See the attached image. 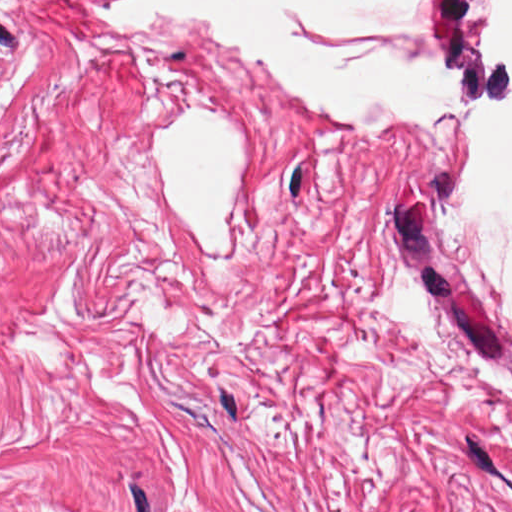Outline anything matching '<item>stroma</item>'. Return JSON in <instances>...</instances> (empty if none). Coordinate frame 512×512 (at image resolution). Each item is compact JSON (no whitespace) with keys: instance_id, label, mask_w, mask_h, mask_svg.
<instances>
[{"instance_id":"stroma-1","label":"stroma","mask_w":512,"mask_h":512,"mask_svg":"<svg viewBox=\"0 0 512 512\" xmlns=\"http://www.w3.org/2000/svg\"><path fill=\"white\" fill-rule=\"evenodd\" d=\"M450 188L0 141V512H512V359Z\"/></svg>"}]
</instances>
